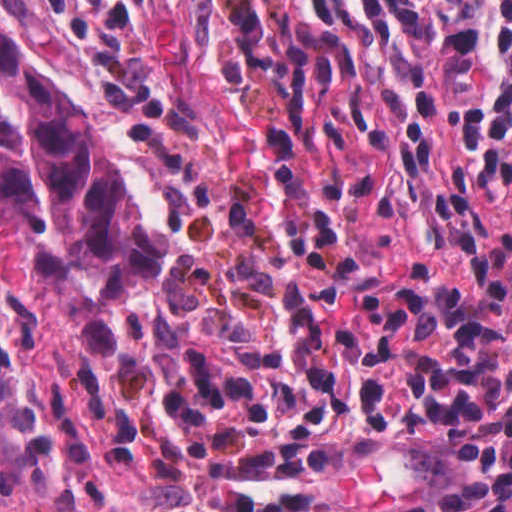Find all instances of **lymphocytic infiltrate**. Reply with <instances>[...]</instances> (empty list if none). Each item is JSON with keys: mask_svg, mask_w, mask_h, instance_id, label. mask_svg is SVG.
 Segmentation results:
<instances>
[{"mask_svg": "<svg viewBox=\"0 0 512 512\" xmlns=\"http://www.w3.org/2000/svg\"><path fill=\"white\" fill-rule=\"evenodd\" d=\"M258 74L360 111L390 149L437 280L512 235V0H243ZM173 370L162 436L307 355L213 346Z\"/></svg>", "mask_w": 512, "mask_h": 512, "instance_id": "1", "label": "lymphocytic infiltrate"}]
</instances>
